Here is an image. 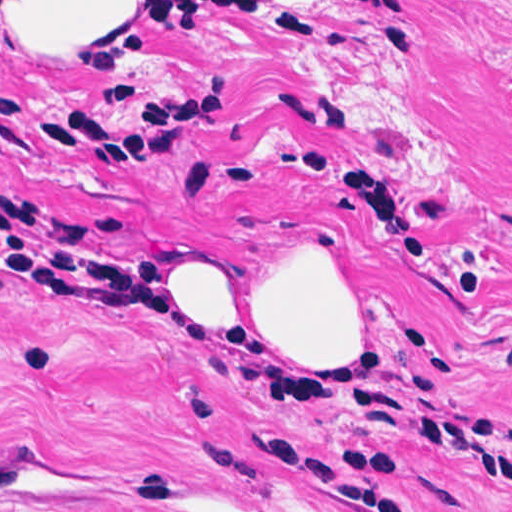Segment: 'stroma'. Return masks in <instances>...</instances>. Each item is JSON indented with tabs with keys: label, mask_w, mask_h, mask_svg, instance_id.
Instances as JSON below:
<instances>
[{
	"label": "stroma",
	"mask_w": 512,
	"mask_h": 512,
	"mask_svg": "<svg viewBox=\"0 0 512 512\" xmlns=\"http://www.w3.org/2000/svg\"><path fill=\"white\" fill-rule=\"evenodd\" d=\"M214 255L346 274L356 359L137 331ZM0 512H512V0L0 9Z\"/></svg>",
	"instance_id": "35a3bbf8"
}]
</instances>
